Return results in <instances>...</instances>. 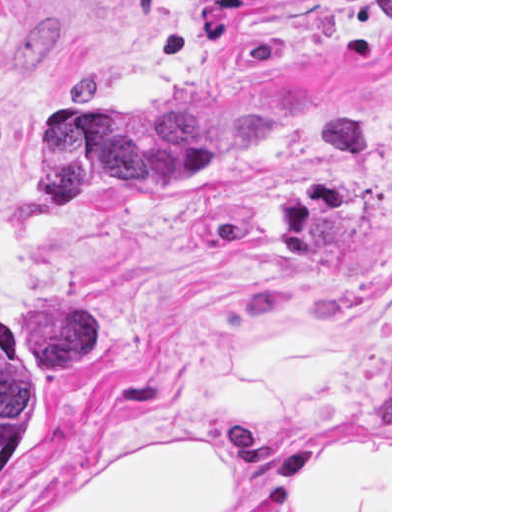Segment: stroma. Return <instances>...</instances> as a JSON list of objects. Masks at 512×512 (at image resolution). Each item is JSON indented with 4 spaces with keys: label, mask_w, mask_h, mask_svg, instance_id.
Instances as JSON below:
<instances>
[{
    "label": "stroma",
    "mask_w": 512,
    "mask_h": 512,
    "mask_svg": "<svg viewBox=\"0 0 512 512\" xmlns=\"http://www.w3.org/2000/svg\"><path fill=\"white\" fill-rule=\"evenodd\" d=\"M271 101L58 202L82 107ZM71 351L0 512H392V0H0V320Z\"/></svg>",
    "instance_id": "stroma-1"
}]
</instances>
